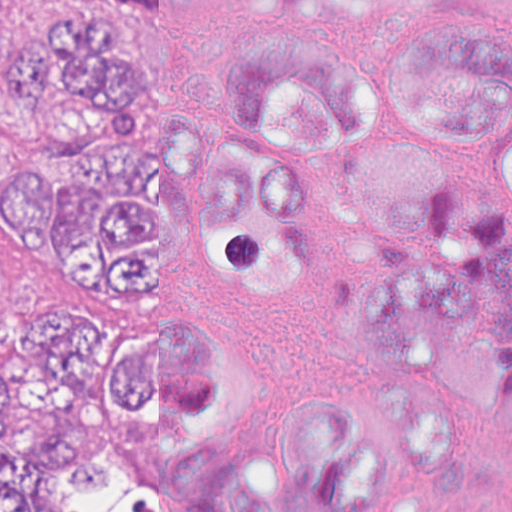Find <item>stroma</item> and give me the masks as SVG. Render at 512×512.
Instances as JSON below:
<instances>
[{"label": "stroma", "mask_w": 512, "mask_h": 512, "mask_svg": "<svg viewBox=\"0 0 512 512\" xmlns=\"http://www.w3.org/2000/svg\"><path fill=\"white\" fill-rule=\"evenodd\" d=\"M72 1L77 0H16V32L32 53L43 25L60 4ZM120 21L144 58V29ZM122 115H144V63ZM41 149L38 121L0 70V160ZM63 304L88 321H144V302L96 305L65 300L11 268L0 250V327H11L40 309Z\"/></svg>", "instance_id": "35a3bbf8"}]
</instances>
